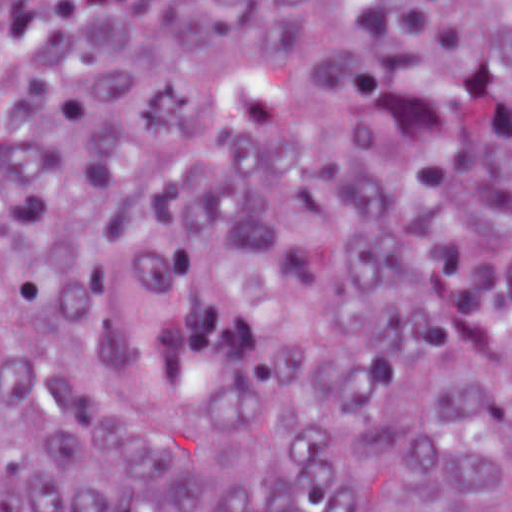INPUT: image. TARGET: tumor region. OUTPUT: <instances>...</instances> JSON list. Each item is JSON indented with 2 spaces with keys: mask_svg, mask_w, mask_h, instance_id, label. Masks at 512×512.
<instances>
[{
  "mask_svg": "<svg viewBox=\"0 0 512 512\" xmlns=\"http://www.w3.org/2000/svg\"><path fill=\"white\" fill-rule=\"evenodd\" d=\"M0 512H512V0H119L29 85Z\"/></svg>",
  "mask_w": 512,
  "mask_h": 512,
  "instance_id": "e687c5a6",
  "label": "tumor region"
}]
</instances>
